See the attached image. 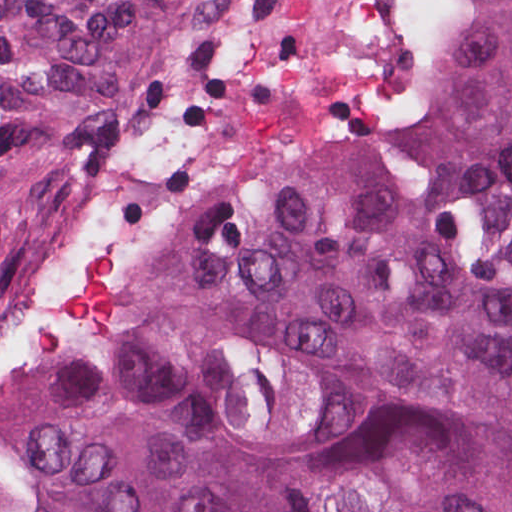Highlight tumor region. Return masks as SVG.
I'll use <instances>...</instances> for the list:
<instances>
[{
    "mask_svg": "<svg viewBox=\"0 0 512 512\" xmlns=\"http://www.w3.org/2000/svg\"><path fill=\"white\" fill-rule=\"evenodd\" d=\"M210 0H0V335ZM17 512H512V0L426 102L179 243Z\"/></svg>",
    "mask_w": 512,
    "mask_h": 512,
    "instance_id": "obj_1",
    "label": "tumor region"
}]
</instances>
